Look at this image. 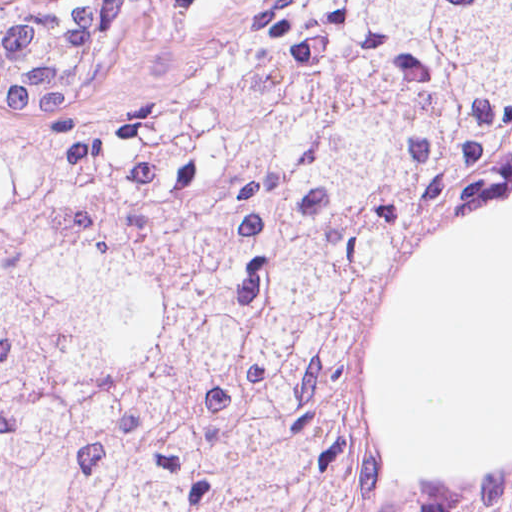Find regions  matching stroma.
<instances>
[{
	"label": "stroma",
	"instance_id": "35a3bbf8",
	"mask_svg": "<svg viewBox=\"0 0 512 512\" xmlns=\"http://www.w3.org/2000/svg\"><path fill=\"white\" fill-rule=\"evenodd\" d=\"M93 1L108 28L95 89L114 109L140 111L192 87L216 69L228 48L216 0Z\"/></svg>",
	"mask_w": 512,
	"mask_h": 512
}]
</instances>
